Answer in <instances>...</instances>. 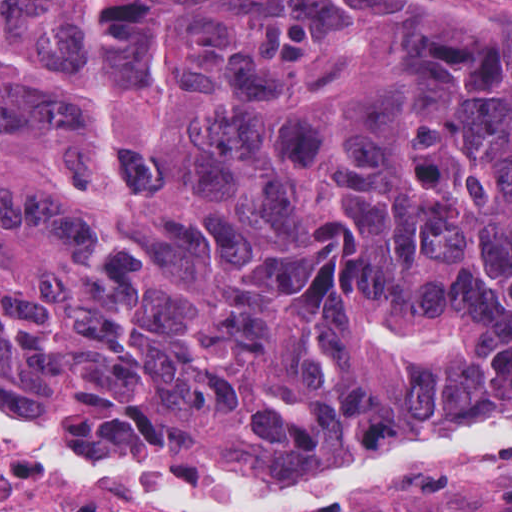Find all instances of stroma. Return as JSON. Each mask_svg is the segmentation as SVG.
<instances>
[{"label": "stroma", "mask_w": 512, "mask_h": 512, "mask_svg": "<svg viewBox=\"0 0 512 512\" xmlns=\"http://www.w3.org/2000/svg\"><path fill=\"white\" fill-rule=\"evenodd\" d=\"M353 1L369 8L427 15L463 30L496 34L512 42V0ZM31 413L73 428L65 416ZM509 419L512 416L470 425ZM470 425L391 438L366 457L334 473L314 477L116 455L125 463L162 473H233L269 481H320L356 473L408 444ZM0 466L26 480L23 499L14 508H26L23 512H160L33 479L1 458ZM304 512H512V441H475L416 456L390 475L328 498Z\"/></svg>", "instance_id": "stroma-1"}]
</instances>
